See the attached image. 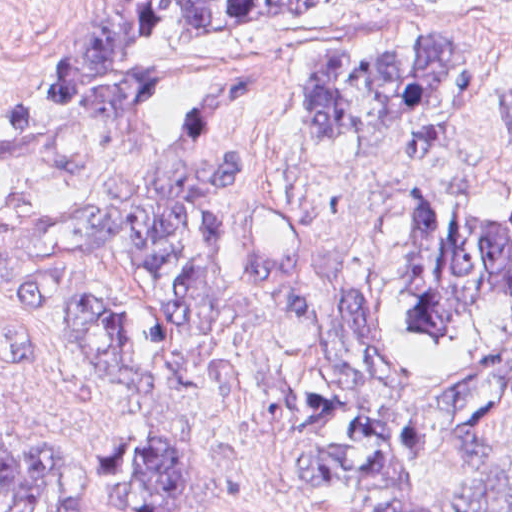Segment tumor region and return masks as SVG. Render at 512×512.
<instances>
[{
    "mask_svg": "<svg viewBox=\"0 0 512 512\" xmlns=\"http://www.w3.org/2000/svg\"><path fill=\"white\" fill-rule=\"evenodd\" d=\"M323 3L85 1L64 63L0 103V158H80L150 136L184 95L310 33ZM294 101L320 150L393 134L404 153L437 154L469 138L466 54L443 23L405 40L307 45ZM498 107L512 149V82ZM255 189L240 160L219 154L102 207L0 210V301L72 331L119 402H145L159 372L132 345L124 311L78 281L88 256L129 263L192 336L270 293L303 336L282 383L290 455L280 472L340 494L411 486L512 427V346L417 379L402 370L399 337L458 344L474 315L512 307V211L489 212L462 187L442 221L406 183L391 317L327 282L282 214L216 215ZM125 458L144 488L108 497L91 460L13 451L0 429V512H175L189 501L174 451L134 443ZM375 512H512V450Z\"/></svg>",
    "mask_w": 512,
    "mask_h": 512,
    "instance_id": "1",
    "label": "tumor region"
}]
</instances>
